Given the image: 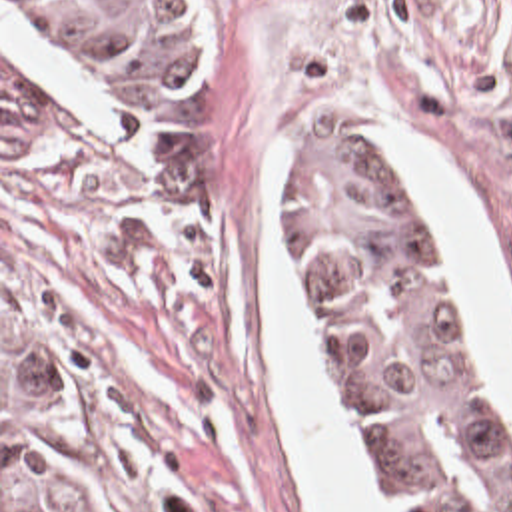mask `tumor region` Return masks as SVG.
<instances>
[{"instance_id":"e687c5a6","label":"tumor region","mask_w":512,"mask_h":512,"mask_svg":"<svg viewBox=\"0 0 512 512\" xmlns=\"http://www.w3.org/2000/svg\"><path fill=\"white\" fill-rule=\"evenodd\" d=\"M98 110H180L214 72L208 0H14ZM46 138V98L2 62V154ZM300 298L405 512H512V477L471 368L463 314L419 244L401 172L321 134L280 190ZM2 512H116L62 372L2 290Z\"/></svg>"}]
</instances>
